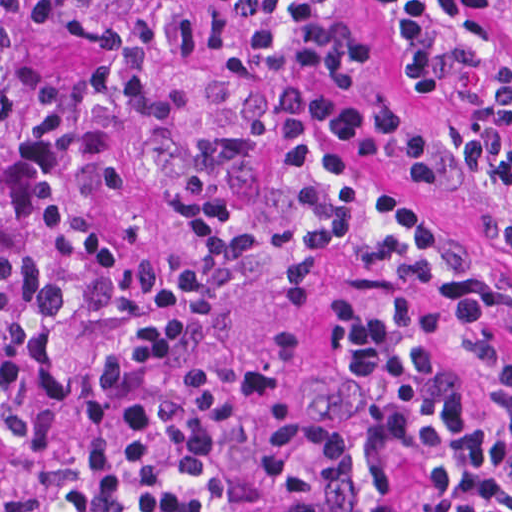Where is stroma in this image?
I'll use <instances>...</instances> for the list:
<instances>
[{
    "label": "stroma",
    "instance_id": "35a3bbf8",
    "mask_svg": "<svg viewBox=\"0 0 512 512\" xmlns=\"http://www.w3.org/2000/svg\"><path fill=\"white\" fill-rule=\"evenodd\" d=\"M362 31V82L370 93L409 107L432 129L426 199L460 245L463 259L493 256L461 163L467 138L502 101L512 109V0H482L498 37V56L482 85L467 94H426L395 70L378 0H345ZM381 269H340L286 305L259 334L254 389L244 417L208 472L180 492L54 493L35 466L0 485V512H236L256 478L253 464L267 437L305 395L329 333L334 306L357 293L429 289ZM512 349V326L498 324ZM389 512H416L411 457L385 458Z\"/></svg>",
    "mask_w": 512,
    "mask_h": 512
}]
</instances>
